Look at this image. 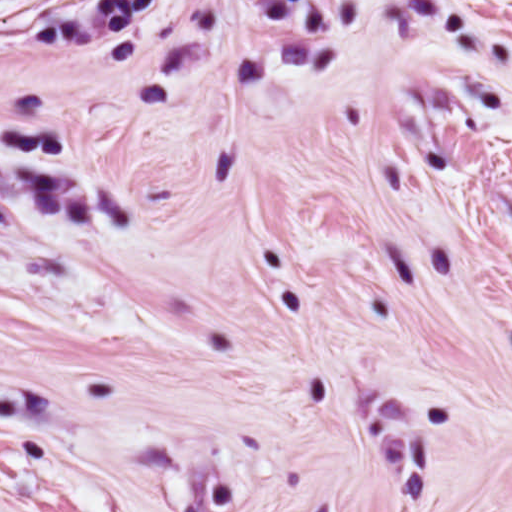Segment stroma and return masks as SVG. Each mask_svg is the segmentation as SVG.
<instances>
[{"mask_svg": "<svg viewBox=\"0 0 512 512\" xmlns=\"http://www.w3.org/2000/svg\"><path fill=\"white\" fill-rule=\"evenodd\" d=\"M387 512H512V457Z\"/></svg>", "mask_w": 512, "mask_h": 512, "instance_id": "obj_1", "label": "stroma"}]
</instances>
